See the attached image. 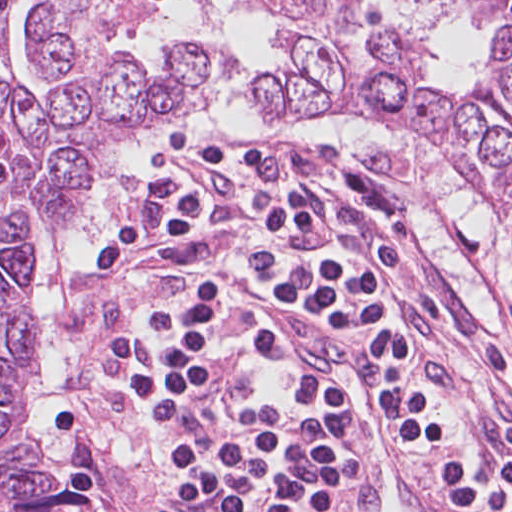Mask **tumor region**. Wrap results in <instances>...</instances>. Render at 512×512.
I'll return each mask as SVG.
<instances>
[{"mask_svg":"<svg viewBox=\"0 0 512 512\" xmlns=\"http://www.w3.org/2000/svg\"><path fill=\"white\" fill-rule=\"evenodd\" d=\"M28 0H0V12ZM30 25L42 76L63 82L40 101L0 78V512H97L91 490L66 494L20 437L22 395L41 360L25 266L36 227L56 239L74 190L127 138L202 116L231 75L227 59L187 47L149 70L121 52L155 0H39ZM199 15L196 3L189 0ZM277 16L284 63L259 71L255 91L272 124L323 118L413 124L486 200L512 237V0H489L487 61L461 93L430 83V48L364 0H243ZM478 11L481 0H428Z\"/></svg>","mask_w":512,"mask_h":512,"instance_id":"tumor-region-1","label":"tumor region"}]
</instances>
